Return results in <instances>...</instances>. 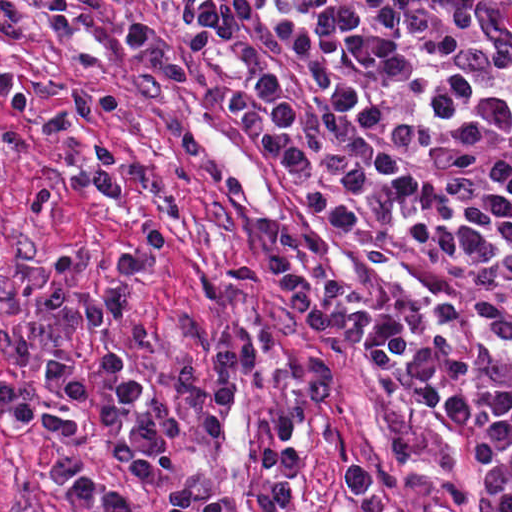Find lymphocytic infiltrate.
I'll list each match as a JSON object with an SVG mask.
<instances>
[{
	"instance_id": "lymphocytic-infiltrate-1",
	"label": "lymphocytic infiltrate",
	"mask_w": 512,
	"mask_h": 512,
	"mask_svg": "<svg viewBox=\"0 0 512 512\" xmlns=\"http://www.w3.org/2000/svg\"><path fill=\"white\" fill-rule=\"evenodd\" d=\"M255 102L227 100L326 222L490 259L437 232L512 186V26L478 1H233Z\"/></svg>"
}]
</instances>
